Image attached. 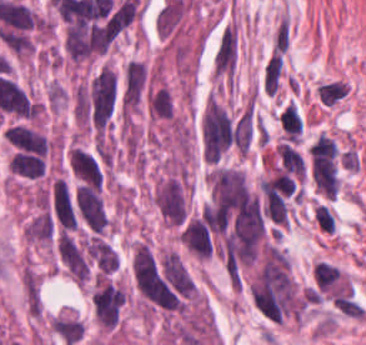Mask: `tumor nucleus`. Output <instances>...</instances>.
<instances>
[{"mask_svg":"<svg viewBox=\"0 0 366 345\" xmlns=\"http://www.w3.org/2000/svg\"><path fill=\"white\" fill-rule=\"evenodd\" d=\"M73 206L75 218L88 232L105 233L108 214L100 188L79 183L74 188Z\"/></svg>","mask_w":366,"mask_h":345,"instance_id":"tumor-nucleus-1","label":"tumor nucleus"},{"mask_svg":"<svg viewBox=\"0 0 366 345\" xmlns=\"http://www.w3.org/2000/svg\"><path fill=\"white\" fill-rule=\"evenodd\" d=\"M154 202L161 215L173 226L187 222L188 206L182 172L162 180Z\"/></svg>","mask_w":366,"mask_h":345,"instance_id":"tumor-nucleus-2","label":"tumor nucleus"},{"mask_svg":"<svg viewBox=\"0 0 366 345\" xmlns=\"http://www.w3.org/2000/svg\"><path fill=\"white\" fill-rule=\"evenodd\" d=\"M147 68L143 62L129 60L121 84L119 105L122 113H131L142 100L147 89Z\"/></svg>","mask_w":366,"mask_h":345,"instance_id":"tumor-nucleus-3","label":"tumor nucleus"},{"mask_svg":"<svg viewBox=\"0 0 366 345\" xmlns=\"http://www.w3.org/2000/svg\"><path fill=\"white\" fill-rule=\"evenodd\" d=\"M122 304V287L98 280L94 308L102 326L113 328L118 323Z\"/></svg>","mask_w":366,"mask_h":345,"instance_id":"tumor-nucleus-4","label":"tumor nucleus"},{"mask_svg":"<svg viewBox=\"0 0 366 345\" xmlns=\"http://www.w3.org/2000/svg\"><path fill=\"white\" fill-rule=\"evenodd\" d=\"M59 255L68 272L77 282H85L89 276V262L72 238L61 232L58 237Z\"/></svg>","mask_w":366,"mask_h":345,"instance_id":"tumor-nucleus-5","label":"tumor nucleus"},{"mask_svg":"<svg viewBox=\"0 0 366 345\" xmlns=\"http://www.w3.org/2000/svg\"><path fill=\"white\" fill-rule=\"evenodd\" d=\"M182 241L197 258H208L212 242L204 212L190 221L183 231Z\"/></svg>","mask_w":366,"mask_h":345,"instance_id":"tumor-nucleus-6","label":"tumor nucleus"},{"mask_svg":"<svg viewBox=\"0 0 366 345\" xmlns=\"http://www.w3.org/2000/svg\"><path fill=\"white\" fill-rule=\"evenodd\" d=\"M69 166L72 172L88 184L102 185V171L95 158L79 148L69 151Z\"/></svg>","mask_w":366,"mask_h":345,"instance_id":"tumor-nucleus-7","label":"tumor nucleus"},{"mask_svg":"<svg viewBox=\"0 0 366 345\" xmlns=\"http://www.w3.org/2000/svg\"><path fill=\"white\" fill-rule=\"evenodd\" d=\"M55 235V220L48 211H40L26 228L25 237L30 242L51 243Z\"/></svg>","mask_w":366,"mask_h":345,"instance_id":"tumor-nucleus-8","label":"tumor nucleus"},{"mask_svg":"<svg viewBox=\"0 0 366 345\" xmlns=\"http://www.w3.org/2000/svg\"><path fill=\"white\" fill-rule=\"evenodd\" d=\"M50 329L67 345H74L84 334V324L76 316L57 315L50 322Z\"/></svg>","mask_w":366,"mask_h":345,"instance_id":"tumor-nucleus-9","label":"tumor nucleus"},{"mask_svg":"<svg viewBox=\"0 0 366 345\" xmlns=\"http://www.w3.org/2000/svg\"><path fill=\"white\" fill-rule=\"evenodd\" d=\"M23 293L30 316L41 314V294L38 276L25 268L22 277Z\"/></svg>","mask_w":366,"mask_h":345,"instance_id":"tumor-nucleus-10","label":"tumor nucleus"},{"mask_svg":"<svg viewBox=\"0 0 366 345\" xmlns=\"http://www.w3.org/2000/svg\"><path fill=\"white\" fill-rule=\"evenodd\" d=\"M148 110L158 118H172L174 106L168 88H154L148 94Z\"/></svg>","mask_w":366,"mask_h":345,"instance_id":"tumor-nucleus-11","label":"tumor nucleus"}]
</instances>
